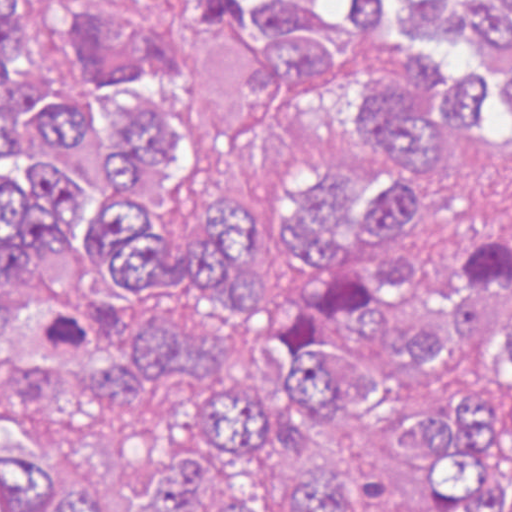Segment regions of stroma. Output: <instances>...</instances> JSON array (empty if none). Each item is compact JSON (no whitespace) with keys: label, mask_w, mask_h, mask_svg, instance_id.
I'll list each match as a JSON object with an SVG mask.
<instances>
[{"label":"stroma","mask_w":512,"mask_h":512,"mask_svg":"<svg viewBox=\"0 0 512 512\" xmlns=\"http://www.w3.org/2000/svg\"><path fill=\"white\" fill-rule=\"evenodd\" d=\"M43 70L53 90L87 69L80 27L88 5L130 17L168 48V73L156 87L206 126L228 130L262 105L265 85L252 54L228 36L190 25L177 0H25ZM316 161L381 165L400 174L419 211L411 248L434 252L512 225V135H484L447 158L405 170L367 154L325 108L287 122L247 147H199L156 211L164 236H188L222 212L247 216L254 233V279L293 273L285 254V189ZM13 414L0 443L34 449L55 464L83 505L139 501L157 462L187 441L194 401L187 383L152 398L144 418L84 414L50 367H5ZM448 399L512 403V365L494 343L453 344L439 383L398 387L380 426H335L293 410L266 444V465L225 466L203 454L224 501L272 505L291 494L299 473L341 479L361 512H441V489L405 463L401 442L428 407Z\"/></svg>","instance_id":"stroma-1"}]
</instances>
